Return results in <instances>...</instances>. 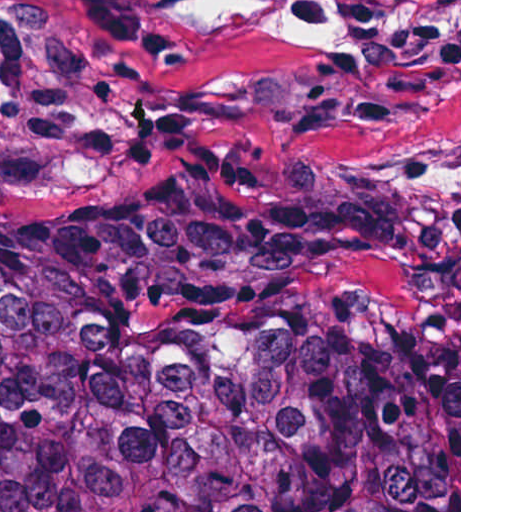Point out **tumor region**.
<instances>
[{
    "mask_svg": "<svg viewBox=\"0 0 512 512\" xmlns=\"http://www.w3.org/2000/svg\"><path fill=\"white\" fill-rule=\"evenodd\" d=\"M0 512H459V389L396 275L0 249Z\"/></svg>",
    "mask_w": 512,
    "mask_h": 512,
    "instance_id": "obj_1",
    "label": "tumor region"
}]
</instances>
